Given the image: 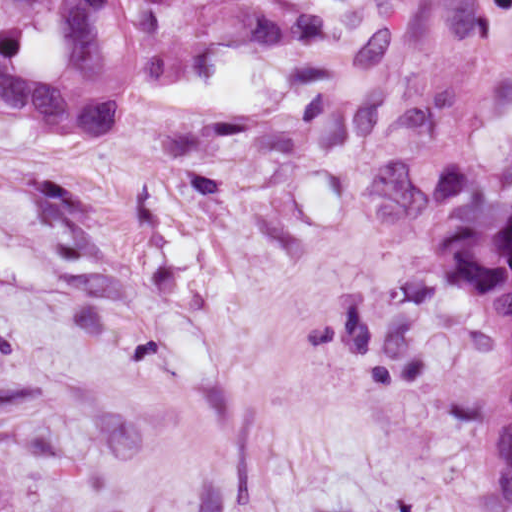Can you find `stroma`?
I'll return each mask as SVG.
<instances>
[{
  "label": "stroma",
  "mask_w": 512,
  "mask_h": 512,
  "mask_svg": "<svg viewBox=\"0 0 512 512\" xmlns=\"http://www.w3.org/2000/svg\"><path fill=\"white\" fill-rule=\"evenodd\" d=\"M300 1L117 137L0 112V512H507L434 170L512 189V0Z\"/></svg>",
  "instance_id": "stroma-1"
}]
</instances>
